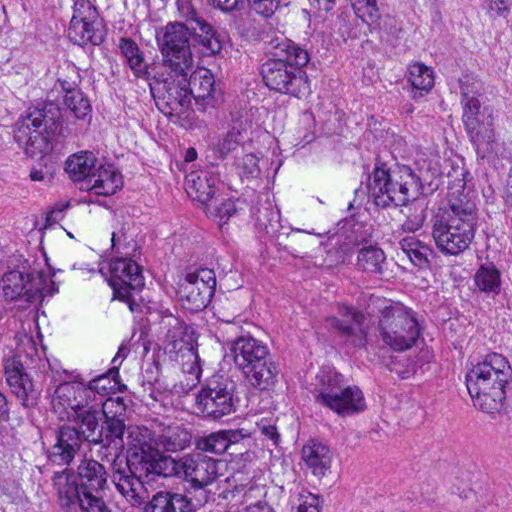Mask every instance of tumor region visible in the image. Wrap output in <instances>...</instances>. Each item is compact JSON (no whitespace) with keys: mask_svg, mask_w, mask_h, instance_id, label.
I'll return each instance as SVG.
<instances>
[{"mask_svg":"<svg viewBox=\"0 0 512 512\" xmlns=\"http://www.w3.org/2000/svg\"><path fill=\"white\" fill-rule=\"evenodd\" d=\"M141 215L512 381V1H0V512H331L374 367Z\"/></svg>","mask_w":512,"mask_h":512,"instance_id":"e687c5a6","label":"tumor region"}]
</instances>
